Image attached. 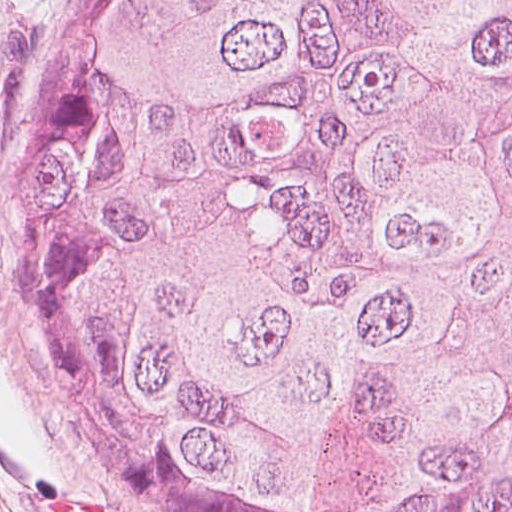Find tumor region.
Wrapping results in <instances>:
<instances>
[{
	"instance_id": "1",
	"label": "tumor region",
	"mask_w": 512,
	"mask_h": 512,
	"mask_svg": "<svg viewBox=\"0 0 512 512\" xmlns=\"http://www.w3.org/2000/svg\"><path fill=\"white\" fill-rule=\"evenodd\" d=\"M0 243L160 511L512 512V0H68Z\"/></svg>"
}]
</instances>
